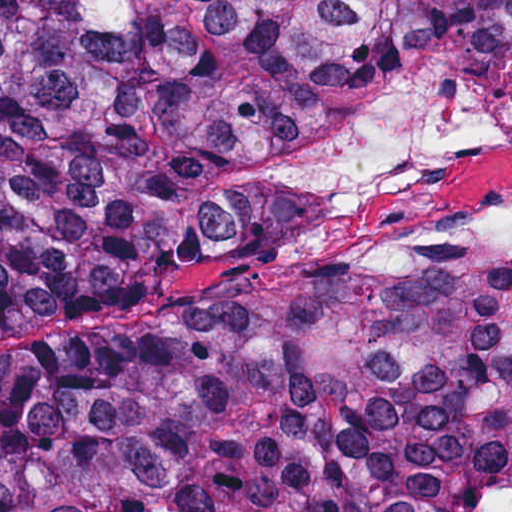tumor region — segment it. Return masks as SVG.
Returning a JSON list of instances; mask_svg holds the SVG:
<instances>
[{
  "mask_svg": "<svg viewBox=\"0 0 512 512\" xmlns=\"http://www.w3.org/2000/svg\"><path fill=\"white\" fill-rule=\"evenodd\" d=\"M423 66L512 89V0H0V299L275 270ZM0 512H512V256L2 355Z\"/></svg>",
  "mask_w": 512,
  "mask_h": 512,
  "instance_id": "e687c5a6",
  "label": "tumor region"
}]
</instances>
